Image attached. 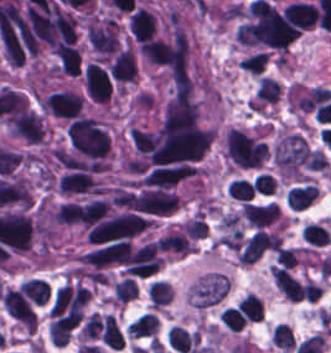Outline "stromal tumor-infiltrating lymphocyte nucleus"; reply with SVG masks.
Masks as SVG:
<instances>
[{
    "instance_id": "obj_1",
    "label": "stromal tumor-infiltrating lymphocyte nucleus",
    "mask_w": 331,
    "mask_h": 353,
    "mask_svg": "<svg viewBox=\"0 0 331 353\" xmlns=\"http://www.w3.org/2000/svg\"><path fill=\"white\" fill-rule=\"evenodd\" d=\"M270 277L281 295L290 302H298L303 294L299 280L281 267L271 265Z\"/></svg>"
},
{
    "instance_id": "obj_2",
    "label": "stromal tumor-infiltrating lymphocyte nucleus",
    "mask_w": 331,
    "mask_h": 353,
    "mask_svg": "<svg viewBox=\"0 0 331 353\" xmlns=\"http://www.w3.org/2000/svg\"><path fill=\"white\" fill-rule=\"evenodd\" d=\"M166 340L170 349L178 353H187L196 345V334L172 324L167 329Z\"/></svg>"
},
{
    "instance_id": "obj_3",
    "label": "stromal tumor-infiltrating lymphocyte nucleus",
    "mask_w": 331,
    "mask_h": 353,
    "mask_svg": "<svg viewBox=\"0 0 331 353\" xmlns=\"http://www.w3.org/2000/svg\"><path fill=\"white\" fill-rule=\"evenodd\" d=\"M317 195V189L310 184L292 187L285 194L286 206L290 210H303Z\"/></svg>"
},
{
    "instance_id": "obj_4",
    "label": "stromal tumor-infiltrating lymphocyte nucleus",
    "mask_w": 331,
    "mask_h": 353,
    "mask_svg": "<svg viewBox=\"0 0 331 353\" xmlns=\"http://www.w3.org/2000/svg\"><path fill=\"white\" fill-rule=\"evenodd\" d=\"M123 341L115 319L110 314H103L100 322V343L111 350H120Z\"/></svg>"
},
{
    "instance_id": "obj_5",
    "label": "stromal tumor-infiltrating lymphocyte nucleus",
    "mask_w": 331,
    "mask_h": 353,
    "mask_svg": "<svg viewBox=\"0 0 331 353\" xmlns=\"http://www.w3.org/2000/svg\"><path fill=\"white\" fill-rule=\"evenodd\" d=\"M146 299L150 308L157 310L172 299V287L167 281L155 278L146 285Z\"/></svg>"
},
{
    "instance_id": "obj_6",
    "label": "stromal tumor-infiltrating lymphocyte nucleus",
    "mask_w": 331,
    "mask_h": 353,
    "mask_svg": "<svg viewBox=\"0 0 331 353\" xmlns=\"http://www.w3.org/2000/svg\"><path fill=\"white\" fill-rule=\"evenodd\" d=\"M135 294L134 281L129 277H121L111 283L109 302L120 307L134 298Z\"/></svg>"
},
{
    "instance_id": "obj_7",
    "label": "stromal tumor-infiltrating lymphocyte nucleus",
    "mask_w": 331,
    "mask_h": 353,
    "mask_svg": "<svg viewBox=\"0 0 331 353\" xmlns=\"http://www.w3.org/2000/svg\"><path fill=\"white\" fill-rule=\"evenodd\" d=\"M300 236L310 246H323L329 241L328 232L320 223H306Z\"/></svg>"
},
{
    "instance_id": "obj_8",
    "label": "stromal tumor-infiltrating lymphocyte nucleus",
    "mask_w": 331,
    "mask_h": 353,
    "mask_svg": "<svg viewBox=\"0 0 331 353\" xmlns=\"http://www.w3.org/2000/svg\"><path fill=\"white\" fill-rule=\"evenodd\" d=\"M300 250L296 247H279L272 265V271L290 268L297 263Z\"/></svg>"
},
{
    "instance_id": "obj_9",
    "label": "stromal tumor-infiltrating lymphocyte nucleus",
    "mask_w": 331,
    "mask_h": 353,
    "mask_svg": "<svg viewBox=\"0 0 331 353\" xmlns=\"http://www.w3.org/2000/svg\"><path fill=\"white\" fill-rule=\"evenodd\" d=\"M229 198L238 201H250L253 199V192L249 180L234 178L230 179L227 186Z\"/></svg>"
},
{
    "instance_id": "obj_10",
    "label": "stromal tumor-infiltrating lymphocyte nucleus",
    "mask_w": 331,
    "mask_h": 353,
    "mask_svg": "<svg viewBox=\"0 0 331 353\" xmlns=\"http://www.w3.org/2000/svg\"><path fill=\"white\" fill-rule=\"evenodd\" d=\"M271 344L290 352L293 349V338L291 331L282 323H275L270 333Z\"/></svg>"
},
{
    "instance_id": "obj_11",
    "label": "stromal tumor-infiltrating lymphocyte nucleus",
    "mask_w": 331,
    "mask_h": 353,
    "mask_svg": "<svg viewBox=\"0 0 331 353\" xmlns=\"http://www.w3.org/2000/svg\"><path fill=\"white\" fill-rule=\"evenodd\" d=\"M221 320L229 332H239L246 318L240 308L227 306L222 311Z\"/></svg>"
},
{
    "instance_id": "obj_12",
    "label": "stromal tumor-infiltrating lymphocyte nucleus",
    "mask_w": 331,
    "mask_h": 353,
    "mask_svg": "<svg viewBox=\"0 0 331 353\" xmlns=\"http://www.w3.org/2000/svg\"><path fill=\"white\" fill-rule=\"evenodd\" d=\"M275 189V179L266 173H259L253 178L252 190L260 195H271Z\"/></svg>"
}]
</instances>
